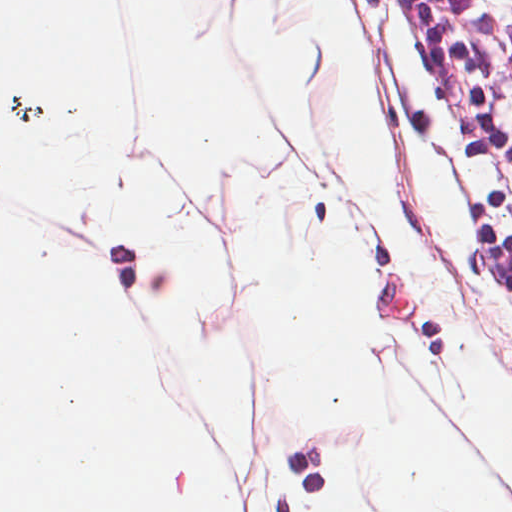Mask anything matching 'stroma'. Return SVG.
Wrapping results in <instances>:
<instances>
[{
  "instance_id": "stroma-1",
  "label": "stroma",
  "mask_w": 512,
  "mask_h": 512,
  "mask_svg": "<svg viewBox=\"0 0 512 512\" xmlns=\"http://www.w3.org/2000/svg\"><path fill=\"white\" fill-rule=\"evenodd\" d=\"M294 2L258 0V10L265 23L282 27L308 13L297 4L292 12ZM341 6L376 99L386 166L409 205L419 255L446 290L414 283L395 231L342 170L347 97L317 43L304 50L300 64L302 120L288 127L279 95L264 85L242 46L241 17L231 64L258 89L284 139L280 151L236 159L221 193L204 190L198 222L221 244L223 297L198 325L205 337L238 346L245 360V444L226 441L176 332L166 372L180 408L229 476L226 512H317L329 505L338 472L352 465L361 478L357 512H397L370 474L363 432L308 424L280 409L254 361L245 296L225 254L239 194L253 169L291 160L342 194L343 216L360 253L364 337L381 348L390 384L395 366L422 376L436 364L458 363L469 346L491 345L492 366L512 372V205L439 59L424 0H341ZM440 400L476 464L512 506V486L482 465Z\"/></svg>"
}]
</instances>
